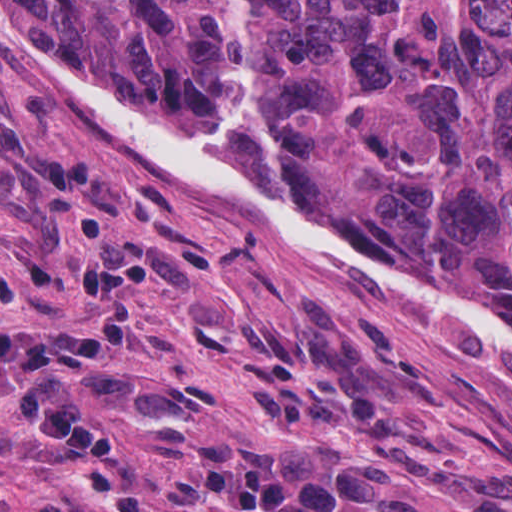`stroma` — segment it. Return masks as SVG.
I'll use <instances>...</instances> for the list:
<instances>
[{
  "instance_id": "obj_1",
  "label": "stroma",
  "mask_w": 512,
  "mask_h": 512,
  "mask_svg": "<svg viewBox=\"0 0 512 512\" xmlns=\"http://www.w3.org/2000/svg\"><path fill=\"white\" fill-rule=\"evenodd\" d=\"M309 178L349 229L395 254L352 212L354 178ZM110 243L162 250L184 273L134 283L138 336L110 351L138 375L187 381L181 398L135 409L76 390L119 435L134 481L188 504L175 486L204 433L312 456L391 439L397 468L376 512H512V367L499 351L173 185L52 101L0 42V270L21 291V309L0 303V323L87 345L98 332L76 281ZM0 494L5 506L57 496L69 512H113L90 459L39 440L3 396Z\"/></svg>"
}]
</instances>
